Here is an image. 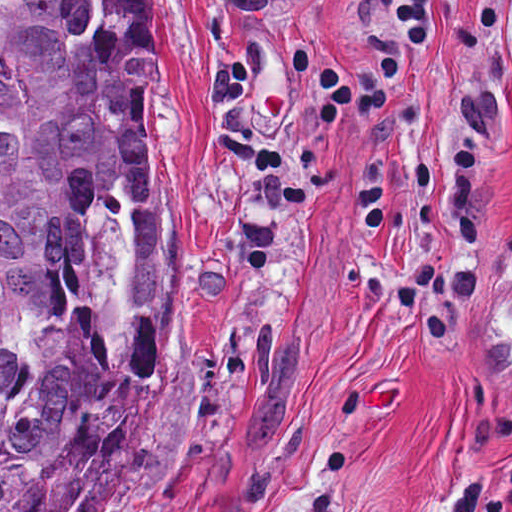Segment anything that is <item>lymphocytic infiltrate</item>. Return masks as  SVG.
<instances>
[{
    "label": "lymphocytic infiltrate",
    "mask_w": 512,
    "mask_h": 512,
    "mask_svg": "<svg viewBox=\"0 0 512 512\" xmlns=\"http://www.w3.org/2000/svg\"><path fill=\"white\" fill-rule=\"evenodd\" d=\"M507 25L509 57L512 61V0H500Z\"/></svg>",
    "instance_id": "lymphocytic-infiltrate-1"
}]
</instances>
